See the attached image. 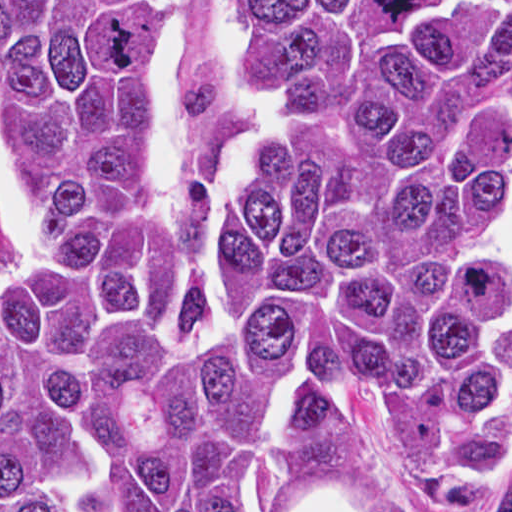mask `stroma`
Segmentation results:
<instances>
[{
  "instance_id": "1",
  "label": "stroma",
  "mask_w": 512,
  "mask_h": 512,
  "mask_svg": "<svg viewBox=\"0 0 512 512\" xmlns=\"http://www.w3.org/2000/svg\"><path fill=\"white\" fill-rule=\"evenodd\" d=\"M0 1H186L178 13L181 44L172 84V151L175 182L182 203L191 206L204 204L213 213L253 134L223 67L222 30L234 1L512 0ZM310 389H325L342 395L359 418L363 431V470L350 492L343 497L359 512H380L406 505H409L413 512H459L433 495L418 473L389 443L378 410L359 398L347 386L339 382L308 386L299 381L273 409H277L296 394Z\"/></svg>"
}]
</instances>
